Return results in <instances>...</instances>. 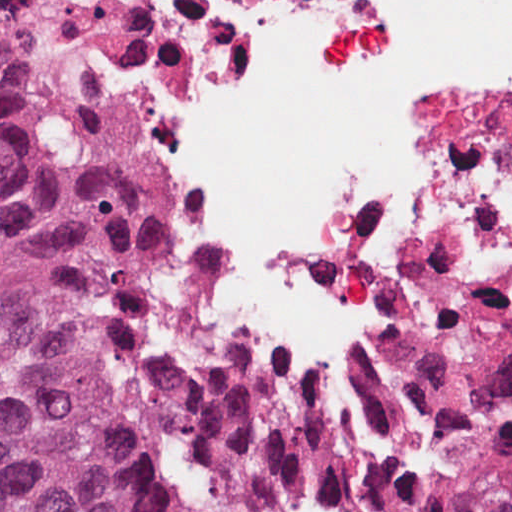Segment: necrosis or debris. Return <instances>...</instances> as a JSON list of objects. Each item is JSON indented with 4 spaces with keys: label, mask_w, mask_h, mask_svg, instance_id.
<instances>
[{
    "label": "necrosis or debris",
    "mask_w": 512,
    "mask_h": 512,
    "mask_svg": "<svg viewBox=\"0 0 512 512\" xmlns=\"http://www.w3.org/2000/svg\"><path fill=\"white\" fill-rule=\"evenodd\" d=\"M142 19L154 181L226 331L428 512H512V0H98Z\"/></svg>",
    "instance_id": "4bbe7bcc"
}]
</instances>
